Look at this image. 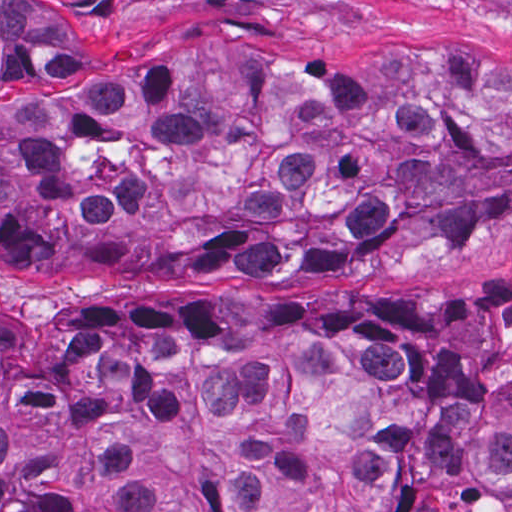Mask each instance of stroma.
<instances>
[{
  "instance_id": "35a3bbf8",
  "label": "stroma",
  "mask_w": 512,
  "mask_h": 512,
  "mask_svg": "<svg viewBox=\"0 0 512 512\" xmlns=\"http://www.w3.org/2000/svg\"><path fill=\"white\" fill-rule=\"evenodd\" d=\"M293 1L188 45H243L329 66H364L412 50L512 56V0H0ZM512 277V228L467 239L426 261H356L342 267L251 278L237 272H168L142 282L36 272L0 262V306L44 315L155 294L237 304L268 294H425L440 282Z\"/></svg>"
}]
</instances>
